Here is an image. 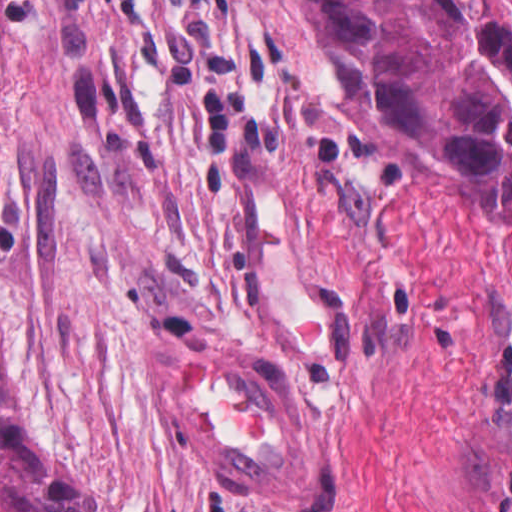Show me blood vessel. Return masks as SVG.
<instances>
[{"label":"blood vessel","mask_w":512,"mask_h":512,"mask_svg":"<svg viewBox=\"0 0 512 512\" xmlns=\"http://www.w3.org/2000/svg\"><path fill=\"white\" fill-rule=\"evenodd\" d=\"M160 426L216 499L322 507L342 484V417L275 330L158 349Z\"/></svg>","instance_id":"obj_1"}]
</instances>
